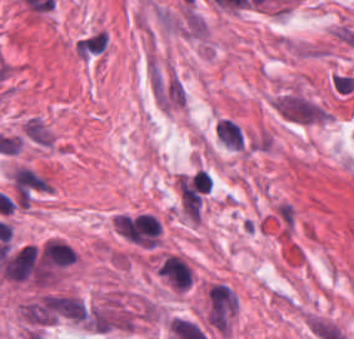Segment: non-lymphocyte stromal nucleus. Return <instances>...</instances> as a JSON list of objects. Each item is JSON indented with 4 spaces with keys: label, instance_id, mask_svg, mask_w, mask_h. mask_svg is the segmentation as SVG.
I'll return each instance as SVG.
<instances>
[{
    "label": "non-lymphocyte stromal nucleus",
    "instance_id": "81446118",
    "mask_svg": "<svg viewBox=\"0 0 354 339\" xmlns=\"http://www.w3.org/2000/svg\"><path fill=\"white\" fill-rule=\"evenodd\" d=\"M25 322L34 327L54 323L45 293L20 307Z\"/></svg>",
    "mask_w": 354,
    "mask_h": 339
},
{
    "label": "non-lymphocyte stromal nucleus",
    "instance_id": "fc2b8d12",
    "mask_svg": "<svg viewBox=\"0 0 354 339\" xmlns=\"http://www.w3.org/2000/svg\"><path fill=\"white\" fill-rule=\"evenodd\" d=\"M110 46L109 31L96 28L78 36L74 48L81 60H93L106 54Z\"/></svg>",
    "mask_w": 354,
    "mask_h": 339
},
{
    "label": "non-lymphocyte stromal nucleus",
    "instance_id": "a72fc3eb",
    "mask_svg": "<svg viewBox=\"0 0 354 339\" xmlns=\"http://www.w3.org/2000/svg\"><path fill=\"white\" fill-rule=\"evenodd\" d=\"M277 110L290 120L312 122L328 120L331 116L326 109L298 94H285L277 100Z\"/></svg>",
    "mask_w": 354,
    "mask_h": 339
},
{
    "label": "non-lymphocyte stromal nucleus",
    "instance_id": "dd21d789",
    "mask_svg": "<svg viewBox=\"0 0 354 339\" xmlns=\"http://www.w3.org/2000/svg\"><path fill=\"white\" fill-rule=\"evenodd\" d=\"M43 314L48 322L85 324L87 320L85 302L72 294H45Z\"/></svg>",
    "mask_w": 354,
    "mask_h": 339
},
{
    "label": "non-lymphocyte stromal nucleus",
    "instance_id": "3746e769",
    "mask_svg": "<svg viewBox=\"0 0 354 339\" xmlns=\"http://www.w3.org/2000/svg\"><path fill=\"white\" fill-rule=\"evenodd\" d=\"M238 307V298L232 288L216 282L207 294L208 322H227Z\"/></svg>",
    "mask_w": 354,
    "mask_h": 339
}]
</instances>
